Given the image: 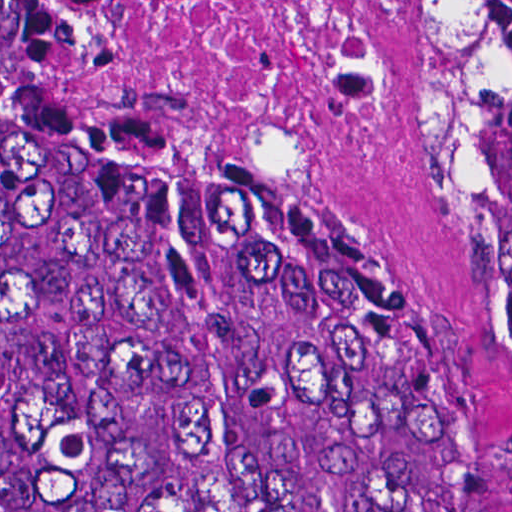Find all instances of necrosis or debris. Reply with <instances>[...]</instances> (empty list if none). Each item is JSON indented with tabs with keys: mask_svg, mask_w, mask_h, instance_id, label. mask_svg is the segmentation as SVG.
<instances>
[{
	"mask_svg": "<svg viewBox=\"0 0 512 512\" xmlns=\"http://www.w3.org/2000/svg\"><path fill=\"white\" fill-rule=\"evenodd\" d=\"M409 0H17L57 143L211 164L380 151L413 100Z\"/></svg>",
	"mask_w": 512,
	"mask_h": 512,
	"instance_id": "4bbe7bcc",
	"label": "necrosis or debris"
}]
</instances>
